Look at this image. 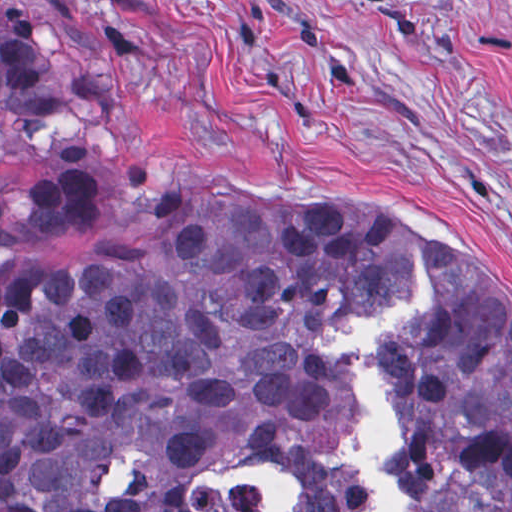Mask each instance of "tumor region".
<instances>
[{"mask_svg": "<svg viewBox=\"0 0 512 512\" xmlns=\"http://www.w3.org/2000/svg\"><path fill=\"white\" fill-rule=\"evenodd\" d=\"M92 128L44 39L0 14V149ZM92 172L0 184V512H255L190 472L291 467L292 512H364L324 461L358 403L319 335L406 297L384 338L409 435L407 512H512V303L466 241L417 223L228 184L163 189L63 264L41 251L95 212Z\"/></svg>", "mask_w": 512, "mask_h": 512, "instance_id": "e687c5a6", "label": "tumor region"}]
</instances>
